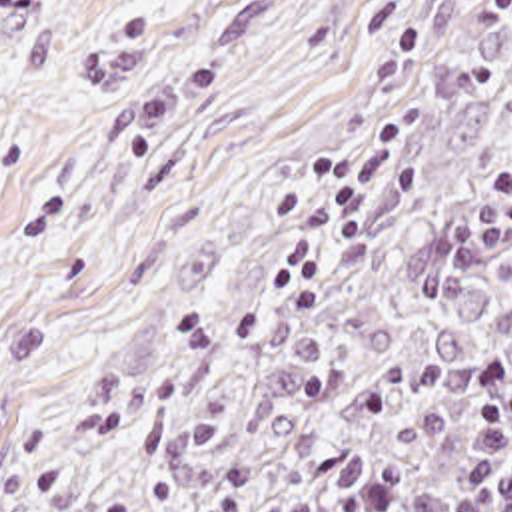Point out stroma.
<instances>
[{"label":"stroma","instance_id":"1","mask_svg":"<svg viewBox=\"0 0 512 512\" xmlns=\"http://www.w3.org/2000/svg\"><path fill=\"white\" fill-rule=\"evenodd\" d=\"M511 44L512 0H0V512L78 503Z\"/></svg>","mask_w":512,"mask_h":512}]
</instances>
